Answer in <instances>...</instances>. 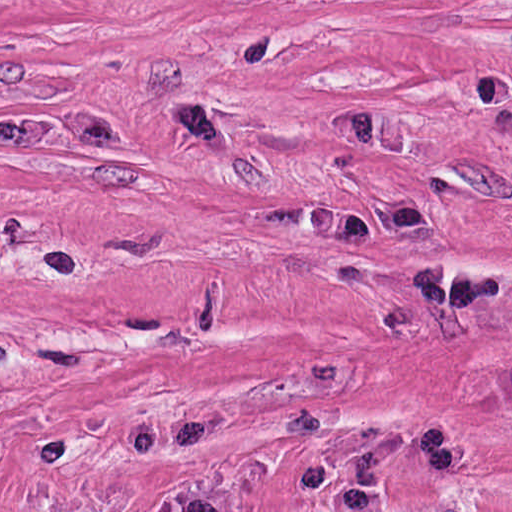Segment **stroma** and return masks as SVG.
Masks as SVG:
<instances>
[{"label":"stroma","mask_w":512,"mask_h":512,"mask_svg":"<svg viewBox=\"0 0 512 512\" xmlns=\"http://www.w3.org/2000/svg\"><path fill=\"white\" fill-rule=\"evenodd\" d=\"M0 298L512 464V0H0Z\"/></svg>","instance_id":"stroma-1"}]
</instances>
